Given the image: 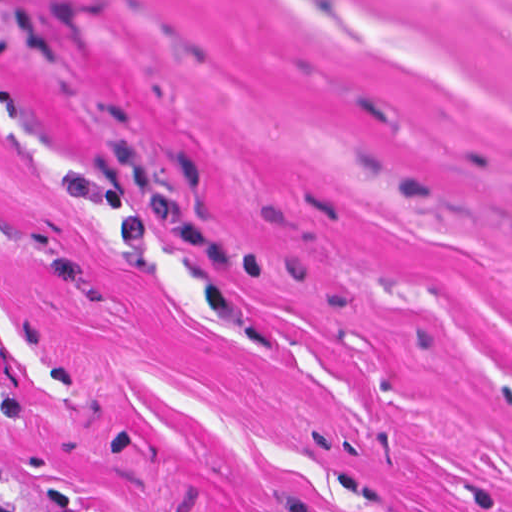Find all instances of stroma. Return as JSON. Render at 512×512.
<instances>
[{
	"instance_id": "obj_1",
	"label": "stroma",
	"mask_w": 512,
	"mask_h": 512,
	"mask_svg": "<svg viewBox=\"0 0 512 512\" xmlns=\"http://www.w3.org/2000/svg\"><path fill=\"white\" fill-rule=\"evenodd\" d=\"M0 492L512 512V0H0Z\"/></svg>"
}]
</instances>
